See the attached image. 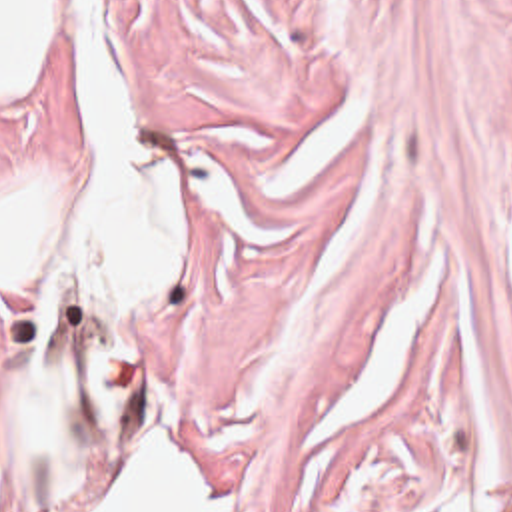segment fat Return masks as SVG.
I'll list each match as a JSON object with an SVG mask.
<instances>
[{"label":"fat","instance_id":"fat-1","mask_svg":"<svg viewBox=\"0 0 512 512\" xmlns=\"http://www.w3.org/2000/svg\"><path fill=\"white\" fill-rule=\"evenodd\" d=\"M62 24V0H0V92H26Z\"/></svg>","mask_w":512,"mask_h":512}]
</instances>
